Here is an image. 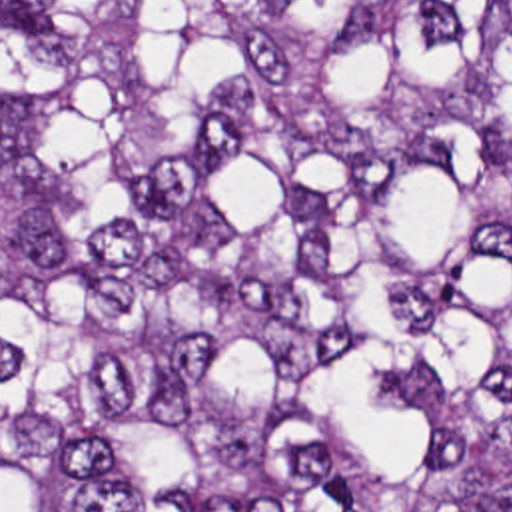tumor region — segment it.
<instances>
[{
    "label": "tumor region",
    "mask_w": 512,
    "mask_h": 512,
    "mask_svg": "<svg viewBox=\"0 0 512 512\" xmlns=\"http://www.w3.org/2000/svg\"><path fill=\"white\" fill-rule=\"evenodd\" d=\"M0 512H512V0H0Z\"/></svg>",
    "instance_id": "1"
}]
</instances>
